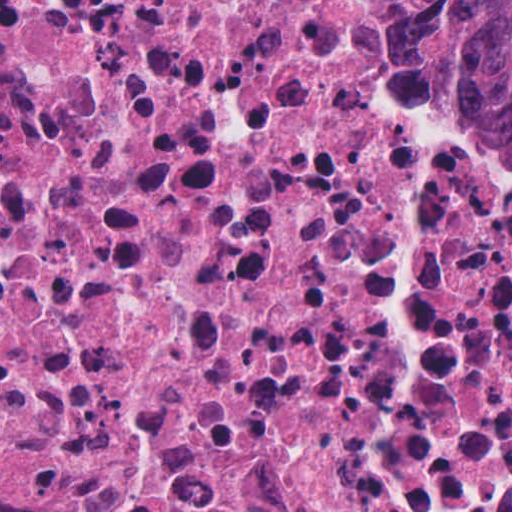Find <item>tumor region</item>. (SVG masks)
<instances>
[{"label": "tumor region", "instance_id": "obj_1", "mask_svg": "<svg viewBox=\"0 0 512 512\" xmlns=\"http://www.w3.org/2000/svg\"><path fill=\"white\" fill-rule=\"evenodd\" d=\"M383 40L512 159V0H389Z\"/></svg>", "mask_w": 512, "mask_h": 512}]
</instances>
